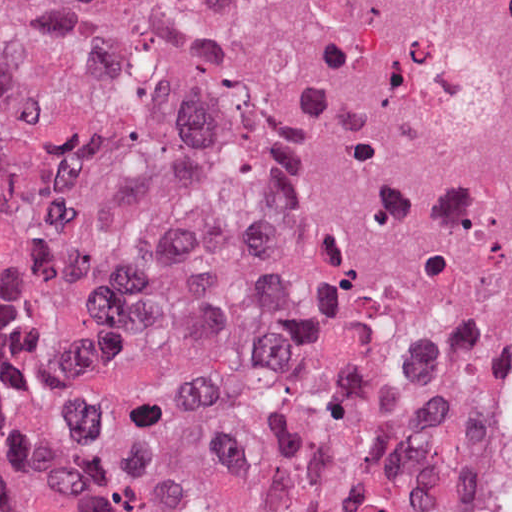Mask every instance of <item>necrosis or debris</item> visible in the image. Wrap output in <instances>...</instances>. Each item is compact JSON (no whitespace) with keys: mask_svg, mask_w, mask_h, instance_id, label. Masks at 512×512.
<instances>
[{"mask_svg":"<svg viewBox=\"0 0 512 512\" xmlns=\"http://www.w3.org/2000/svg\"><path fill=\"white\" fill-rule=\"evenodd\" d=\"M277 282L473 416L512 339V0H104Z\"/></svg>","mask_w":512,"mask_h":512,"instance_id":"necrosis-or-debris-1","label":"necrosis or debris"}]
</instances>
